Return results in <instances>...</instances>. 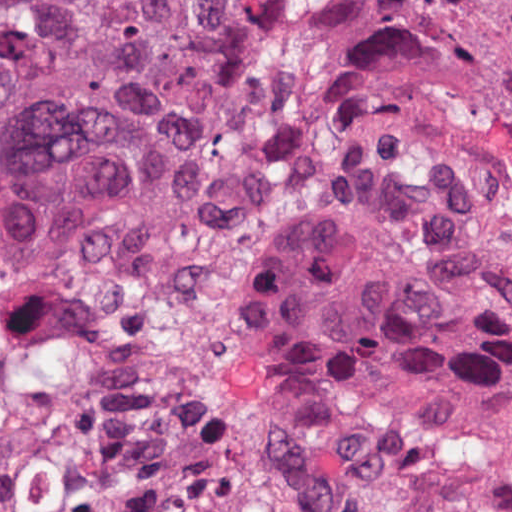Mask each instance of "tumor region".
I'll return each mask as SVG.
<instances>
[{"label":"tumor region","instance_id":"1","mask_svg":"<svg viewBox=\"0 0 512 512\" xmlns=\"http://www.w3.org/2000/svg\"><path fill=\"white\" fill-rule=\"evenodd\" d=\"M377 108L405 132L275 295L254 398L321 441L512 442V0H0V259L219 208Z\"/></svg>","mask_w":512,"mask_h":512}]
</instances>
